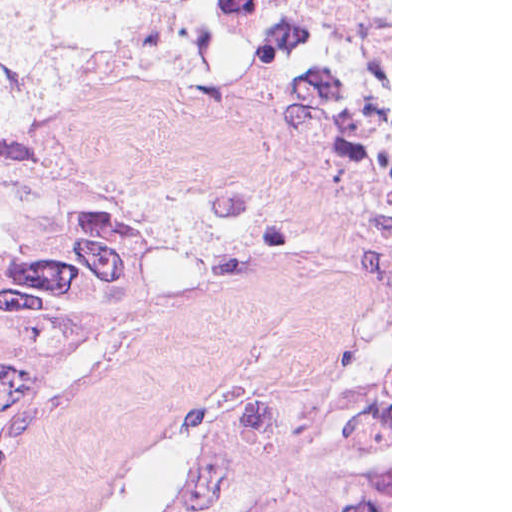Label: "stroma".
Segmentation results:
<instances>
[{
	"instance_id": "1",
	"label": "stroma",
	"mask_w": 512,
	"mask_h": 512,
	"mask_svg": "<svg viewBox=\"0 0 512 512\" xmlns=\"http://www.w3.org/2000/svg\"><path fill=\"white\" fill-rule=\"evenodd\" d=\"M16 108L73 117L170 202L160 288L63 367L16 487L177 512L229 423L240 512L291 507L315 458L357 440H390L392 512V0L306 21L0 0Z\"/></svg>"
}]
</instances>
